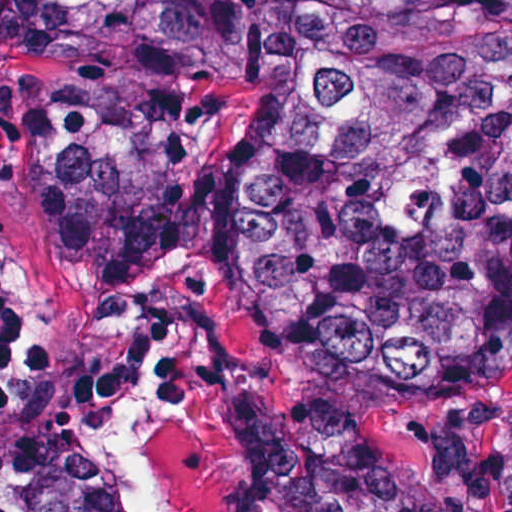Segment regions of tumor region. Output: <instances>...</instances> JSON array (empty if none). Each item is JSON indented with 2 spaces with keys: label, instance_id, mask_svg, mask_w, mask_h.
Here are the masks:
<instances>
[{
  "label": "tumor region",
  "instance_id": "obj_1",
  "mask_svg": "<svg viewBox=\"0 0 512 512\" xmlns=\"http://www.w3.org/2000/svg\"><path fill=\"white\" fill-rule=\"evenodd\" d=\"M57 74L40 248L87 275L171 263L206 96L262 83L223 241L249 324L314 391L242 397L238 512H458L381 436L512 386V0H57ZM0 512L135 511L94 455L0 448Z\"/></svg>",
  "mask_w": 512,
  "mask_h": 512
}]
</instances>
